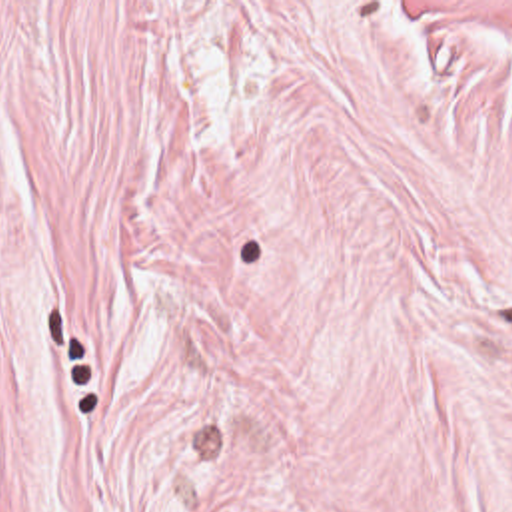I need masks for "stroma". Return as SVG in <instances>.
Returning <instances> with one entry per match:
<instances>
[{"label":"stroma","instance_id":"1","mask_svg":"<svg viewBox=\"0 0 512 512\" xmlns=\"http://www.w3.org/2000/svg\"><path fill=\"white\" fill-rule=\"evenodd\" d=\"M0 512H512V0H0Z\"/></svg>","mask_w":512,"mask_h":512}]
</instances>
